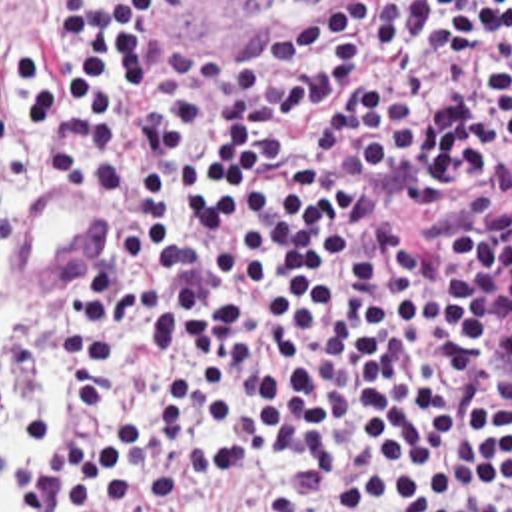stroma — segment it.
<instances>
[{"label": "stroma", "mask_w": 512, "mask_h": 512, "mask_svg": "<svg viewBox=\"0 0 512 512\" xmlns=\"http://www.w3.org/2000/svg\"><path fill=\"white\" fill-rule=\"evenodd\" d=\"M1 48H29L31 54L35 56L37 64L47 58V0H0V56ZM0 146H15L25 152L21 130L9 118V114L3 106V100H1V92ZM45 178H51V176L39 168V174L29 182L25 192L33 184H37ZM23 194L17 202L13 216H11L9 242H11L15 220H17L19 208H21ZM111 220H113V198H111ZM37 298L67 302L69 282H65ZM45 420H47V434H49L55 426V416L45 418ZM5 448H7L9 462L15 469L17 487H19V507L15 512H21L23 509V477H21L19 465L11 454V426L7 432ZM278 493H280V475H209L181 503L215 505L223 511H264L278 497ZM157 507H161V505H157ZM157 507H149V509H157Z\"/></svg>", "instance_id": "obj_1"}]
</instances>
